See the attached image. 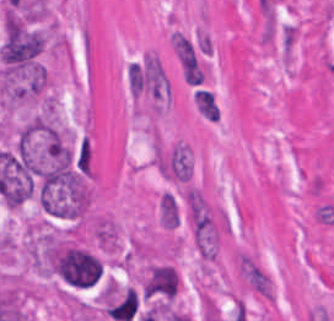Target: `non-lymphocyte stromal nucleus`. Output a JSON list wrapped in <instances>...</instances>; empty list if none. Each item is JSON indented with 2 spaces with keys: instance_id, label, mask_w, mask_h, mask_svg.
<instances>
[{
  "instance_id": "1",
  "label": "non-lymphocyte stromal nucleus",
  "mask_w": 334,
  "mask_h": 321,
  "mask_svg": "<svg viewBox=\"0 0 334 321\" xmlns=\"http://www.w3.org/2000/svg\"><path fill=\"white\" fill-rule=\"evenodd\" d=\"M92 235L102 250L114 251L118 232L115 225L107 219L95 218L91 225Z\"/></svg>"
},
{
  "instance_id": "2",
  "label": "non-lymphocyte stromal nucleus",
  "mask_w": 334,
  "mask_h": 321,
  "mask_svg": "<svg viewBox=\"0 0 334 321\" xmlns=\"http://www.w3.org/2000/svg\"><path fill=\"white\" fill-rule=\"evenodd\" d=\"M157 217L162 228L172 229L177 225L179 212L175 197L169 193H162L157 202Z\"/></svg>"
}]
</instances>
